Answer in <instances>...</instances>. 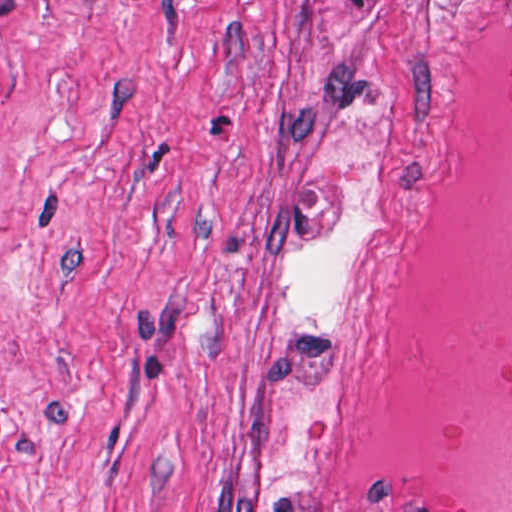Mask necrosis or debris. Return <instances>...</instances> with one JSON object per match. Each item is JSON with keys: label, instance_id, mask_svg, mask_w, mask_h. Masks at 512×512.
I'll use <instances>...</instances> for the list:
<instances>
[{"label": "necrosis or debris", "instance_id": "obj_1", "mask_svg": "<svg viewBox=\"0 0 512 512\" xmlns=\"http://www.w3.org/2000/svg\"><path fill=\"white\" fill-rule=\"evenodd\" d=\"M321 362L360 512H512V0H439L396 66Z\"/></svg>", "mask_w": 512, "mask_h": 512}]
</instances>
